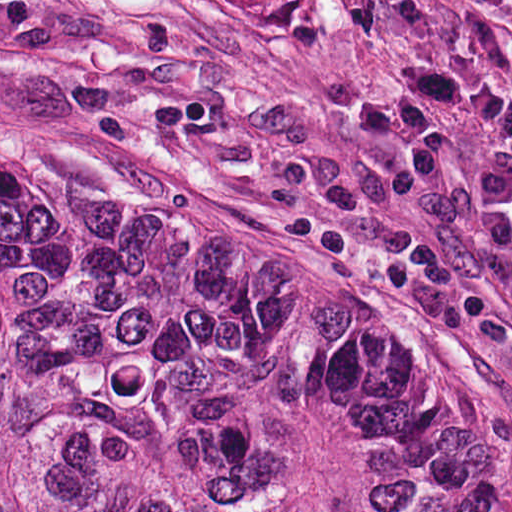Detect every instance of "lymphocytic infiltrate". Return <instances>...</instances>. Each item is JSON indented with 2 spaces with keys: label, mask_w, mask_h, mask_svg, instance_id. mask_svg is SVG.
Returning <instances> with one entry per match:
<instances>
[{
  "label": "lymphocytic infiltrate",
  "mask_w": 512,
  "mask_h": 512,
  "mask_svg": "<svg viewBox=\"0 0 512 512\" xmlns=\"http://www.w3.org/2000/svg\"><path fill=\"white\" fill-rule=\"evenodd\" d=\"M398 84L363 90L342 112L349 125L372 140L401 150L412 169L433 176L442 140L437 119L458 112L508 137L512 143V90L490 84L458 61L436 53L397 63ZM484 217V232L503 251L512 248V147L477 167L467 179Z\"/></svg>",
  "instance_id": "1"
}]
</instances>
